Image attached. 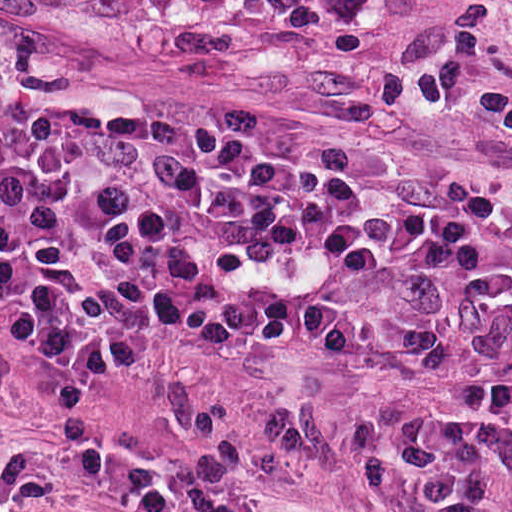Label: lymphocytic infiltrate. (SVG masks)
Masks as SVG:
<instances>
[{
  "mask_svg": "<svg viewBox=\"0 0 512 512\" xmlns=\"http://www.w3.org/2000/svg\"><path fill=\"white\" fill-rule=\"evenodd\" d=\"M0 330L43 384H119L207 430L229 418L154 368L164 340L260 367L294 341L375 344L512 452V190L0 125Z\"/></svg>",
  "mask_w": 512,
  "mask_h": 512,
  "instance_id": "obj_1",
  "label": "lymphocytic infiltrate"
}]
</instances>
